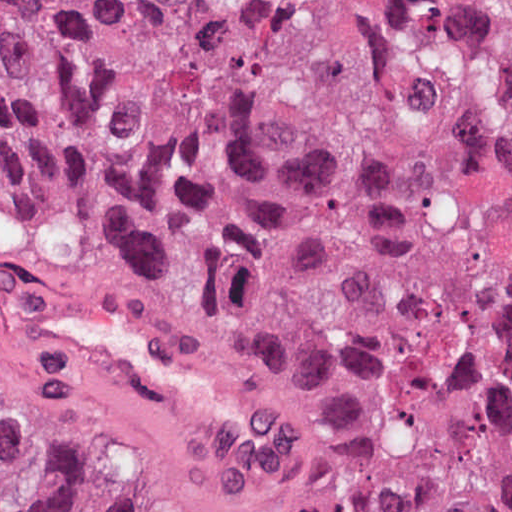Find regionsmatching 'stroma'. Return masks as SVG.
<instances>
[{
	"label": "stroma",
	"mask_w": 512,
	"mask_h": 512,
	"mask_svg": "<svg viewBox=\"0 0 512 512\" xmlns=\"http://www.w3.org/2000/svg\"><path fill=\"white\" fill-rule=\"evenodd\" d=\"M73 290L129 307L226 370L250 401L254 422L236 427L77 352L46 316L39 289ZM3 323L27 349L84 376L188 448L186 484L229 467L298 425V405L273 367L238 334L151 288L111 277L39 240L21 244L3 282Z\"/></svg>",
	"instance_id": "obj_1"
}]
</instances>
